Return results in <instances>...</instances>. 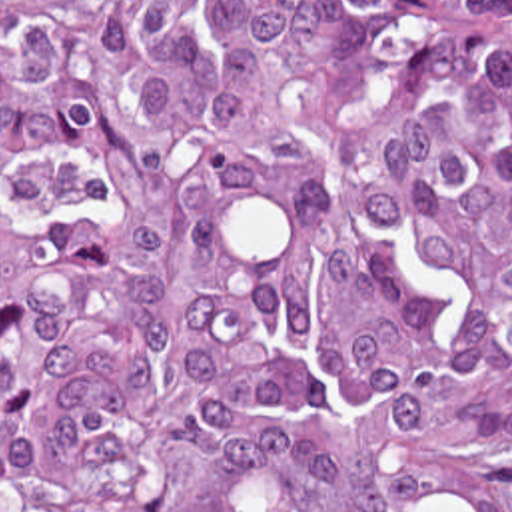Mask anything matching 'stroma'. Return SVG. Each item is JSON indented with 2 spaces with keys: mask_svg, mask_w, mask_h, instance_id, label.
I'll return each instance as SVG.
<instances>
[{
  "mask_svg": "<svg viewBox=\"0 0 512 512\" xmlns=\"http://www.w3.org/2000/svg\"><path fill=\"white\" fill-rule=\"evenodd\" d=\"M25 0H0V10ZM480 469L490 489L512 511V424H468ZM0 512H7L0 509Z\"/></svg>",
  "mask_w": 512,
  "mask_h": 512,
  "instance_id": "stroma-1",
  "label": "stroma"
}]
</instances>
